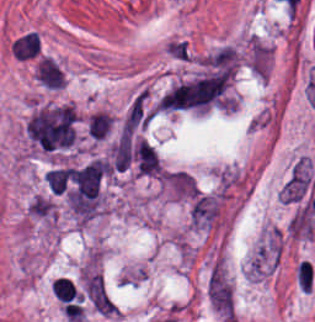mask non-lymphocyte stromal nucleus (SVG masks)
Segmentation results:
<instances>
[{
    "label": "non-lymphocyte stromal nucleus",
    "mask_w": 315,
    "mask_h": 322,
    "mask_svg": "<svg viewBox=\"0 0 315 322\" xmlns=\"http://www.w3.org/2000/svg\"><path fill=\"white\" fill-rule=\"evenodd\" d=\"M83 295L90 307L100 315H112L114 303L100 274H87L83 280Z\"/></svg>",
    "instance_id": "obj_2"
},
{
    "label": "non-lymphocyte stromal nucleus",
    "mask_w": 315,
    "mask_h": 322,
    "mask_svg": "<svg viewBox=\"0 0 315 322\" xmlns=\"http://www.w3.org/2000/svg\"><path fill=\"white\" fill-rule=\"evenodd\" d=\"M162 188L176 200H191L201 189L196 179L186 171L166 169L161 176Z\"/></svg>",
    "instance_id": "obj_1"
}]
</instances>
